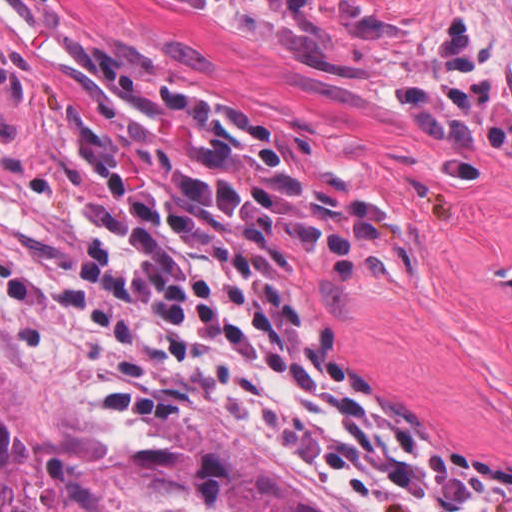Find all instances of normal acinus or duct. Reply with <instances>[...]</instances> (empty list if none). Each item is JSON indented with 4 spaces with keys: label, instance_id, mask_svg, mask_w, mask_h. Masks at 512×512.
Wrapping results in <instances>:
<instances>
[{
    "label": "normal acinus or duct",
    "instance_id": "obj_1",
    "mask_svg": "<svg viewBox=\"0 0 512 512\" xmlns=\"http://www.w3.org/2000/svg\"><path fill=\"white\" fill-rule=\"evenodd\" d=\"M479 278L512 296V258H494L482 263Z\"/></svg>",
    "mask_w": 512,
    "mask_h": 512
}]
</instances>
